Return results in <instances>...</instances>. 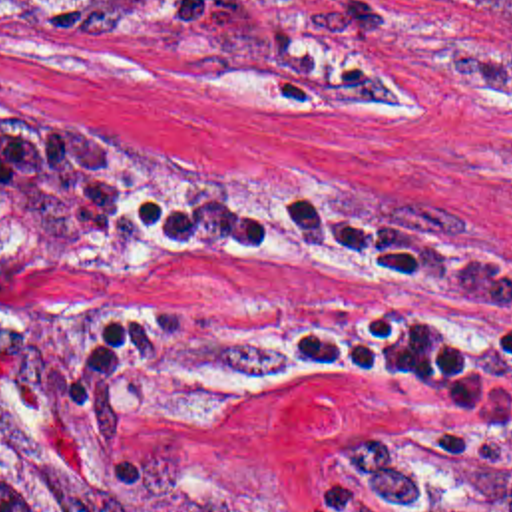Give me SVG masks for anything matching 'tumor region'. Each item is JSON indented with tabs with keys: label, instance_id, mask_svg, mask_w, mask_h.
Returning <instances> with one entry per match:
<instances>
[{
	"label": "tumor region",
	"instance_id": "e687c5a6",
	"mask_svg": "<svg viewBox=\"0 0 512 512\" xmlns=\"http://www.w3.org/2000/svg\"><path fill=\"white\" fill-rule=\"evenodd\" d=\"M27 0H0L23 3ZM135 512H260L244 487L218 475L196 449L153 433L121 451ZM0 512H61V475L35 431L0 411Z\"/></svg>",
	"mask_w": 512,
	"mask_h": 512
}]
</instances>
